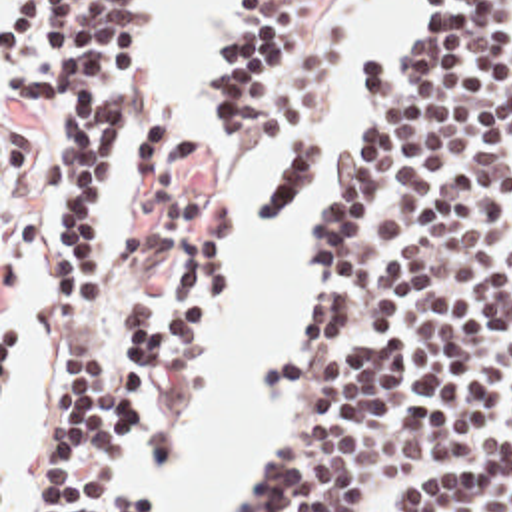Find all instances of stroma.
<instances>
[{
  "mask_svg": "<svg viewBox=\"0 0 512 512\" xmlns=\"http://www.w3.org/2000/svg\"><path fill=\"white\" fill-rule=\"evenodd\" d=\"M10 0H0V512H24V458L32 438L42 430L48 410V386L56 364L58 332V262L56 232L76 192L52 196L42 188V128L10 110L2 100V16ZM142 8L144 54L148 62V108L174 116L210 156L214 174L208 196L186 240H214L228 258V300L224 328L210 354L194 370L192 388L220 360L238 308L236 258L224 238L214 232V194L224 176L244 172L252 192V260L270 268L288 244L297 216L305 204V296L296 350L278 364L297 358L307 340L309 316L317 298V252L329 226V192L325 184L327 158L349 160L361 136L363 106L353 90L359 68L375 62L389 76L399 72L415 40L407 0H353L345 10L347 54L335 72L333 92L323 124V144L305 182L288 202L280 224L264 242L260 190L274 166L278 144L274 138H250L230 152L212 146L202 110V74L196 106H164L156 98L150 70L152 0H138ZM238 0H230L218 18L206 62L228 34ZM507 4L512 0H493ZM204 62V66H206ZM204 70V68H202ZM136 186L116 180L104 198L98 226L104 238L106 280L122 292L150 288L158 302L170 296V260H154L134 240ZM278 364L262 376L260 398L274 410L282 432L272 454L252 462L236 482L224 512L240 482L278 456L294 418L297 396L274 392ZM192 374L158 400L150 422H174L182 450L174 462L146 472L134 464L124 492L158 498L160 512H170V502L160 484L174 478L188 442V390Z\"/></svg>",
  "mask_w": 512,
  "mask_h": 512,
  "instance_id": "obj_1",
  "label": "stroma"
}]
</instances>
